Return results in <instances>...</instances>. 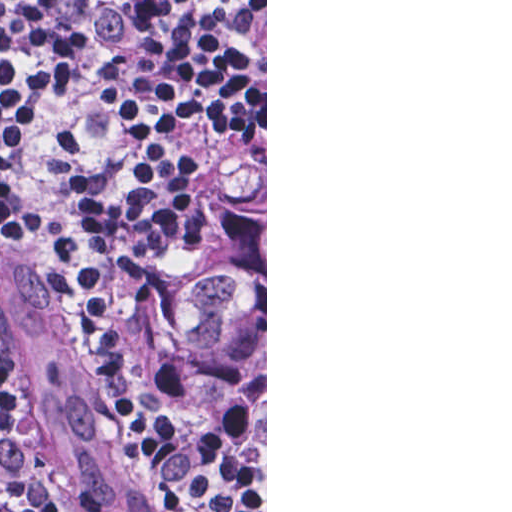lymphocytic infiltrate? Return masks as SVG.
Segmentation results:
<instances>
[{"label":"lymphocytic infiltrate","mask_w":512,"mask_h":512,"mask_svg":"<svg viewBox=\"0 0 512 512\" xmlns=\"http://www.w3.org/2000/svg\"><path fill=\"white\" fill-rule=\"evenodd\" d=\"M265 148V0H0V213L54 254L174 512H251L170 444L111 317L178 252L190 152ZM0 512H31L0 385Z\"/></svg>","instance_id":"obj_1"}]
</instances>
